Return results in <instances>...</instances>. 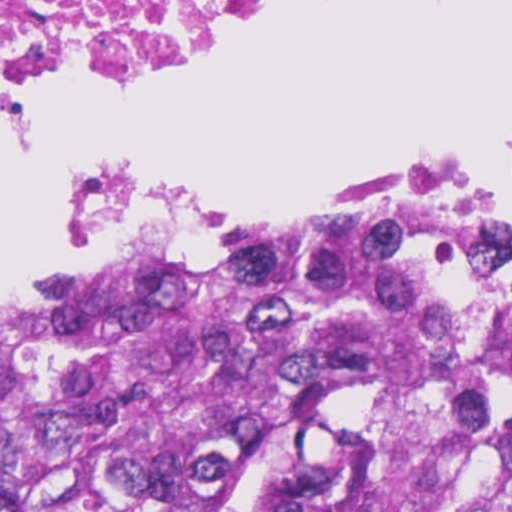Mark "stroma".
I'll list each match as a JSON object with an SVG mask.
<instances>
[{
	"instance_id": "stroma-1",
	"label": "stroma",
	"mask_w": 512,
	"mask_h": 512,
	"mask_svg": "<svg viewBox=\"0 0 512 512\" xmlns=\"http://www.w3.org/2000/svg\"><path fill=\"white\" fill-rule=\"evenodd\" d=\"M259 30H261V29H257L255 31H252L250 33L242 35V36L235 38L233 40H230L228 42H225V43L207 48L205 50H202L184 62L196 59L198 57L213 53L220 49H224L226 47H229L231 45L239 43V42L247 39L251 35L255 34ZM103 93H106V92H103ZM390 205H423V206L437 209L422 199H393V200H389V201H385V202H381V203H377V204L347 208V209H345L341 212H338L330 217H327L321 221H318L313 224L304 226L302 228L293 230L291 232L279 235L274 238L256 240V241H250V242H243V243H237V244H289L307 234H311V233L319 232L322 230L337 227L341 224H344V223H346L350 220H353L357 217H360L364 214L376 211L378 209H381V208H384V207H387ZM137 251H139V250H137ZM134 252H136V251L121 254L118 256L110 257V258H106V259L86 265L81 268L60 271V272H0V291H13V290H17V289H21V288H25V287H29V286L41 284V283H44V282H47V281H50V280H53L56 278H60V277L84 270V269H88V268L106 263L108 261L120 258L122 256L131 254Z\"/></svg>"
}]
</instances>
